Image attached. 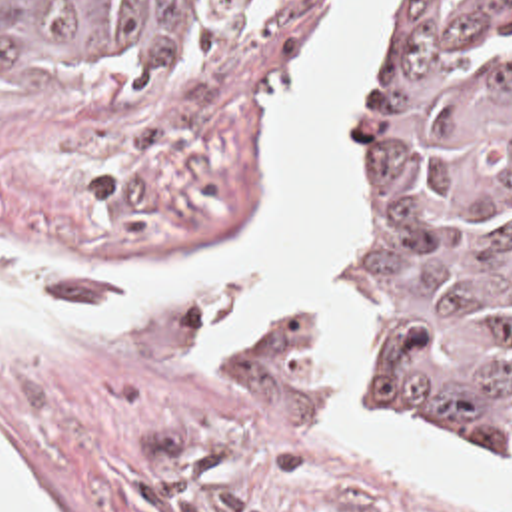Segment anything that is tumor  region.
Masks as SVG:
<instances>
[{"label":"tumor region","instance_id":"tumor-region-1","mask_svg":"<svg viewBox=\"0 0 512 512\" xmlns=\"http://www.w3.org/2000/svg\"><path fill=\"white\" fill-rule=\"evenodd\" d=\"M267 0H0L47 83H157ZM369 315L389 416L512 446V0H405L365 117Z\"/></svg>","mask_w":512,"mask_h":512}]
</instances>
